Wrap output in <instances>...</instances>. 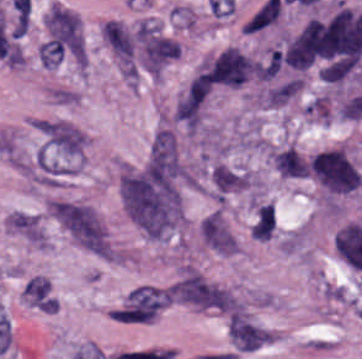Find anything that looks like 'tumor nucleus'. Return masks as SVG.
<instances>
[{
    "instance_id": "obj_3",
    "label": "tumor nucleus",
    "mask_w": 362,
    "mask_h": 359,
    "mask_svg": "<svg viewBox=\"0 0 362 359\" xmlns=\"http://www.w3.org/2000/svg\"><path fill=\"white\" fill-rule=\"evenodd\" d=\"M269 159L274 169L289 178L306 177L304 156L294 146H285L269 152Z\"/></svg>"
},
{
    "instance_id": "obj_2",
    "label": "tumor nucleus",
    "mask_w": 362,
    "mask_h": 359,
    "mask_svg": "<svg viewBox=\"0 0 362 359\" xmlns=\"http://www.w3.org/2000/svg\"><path fill=\"white\" fill-rule=\"evenodd\" d=\"M254 69L252 58L234 47H227L204 71L211 82L239 86Z\"/></svg>"
},
{
    "instance_id": "obj_1",
    "label": "tumor nucleus",
    "mask_w": 362,
    "mask_h": 359,
    "mask_svg": "<svg viewBox=\"0 0 362 359\" xmlns=\"http://www.w3.org/2000/svg\"><path fill=\"white\" fill-rule=\"evenodd\" d=\"M309 174L332 195L349 194L362 186V173L346 148L332 146L305 160Z\"/></svg>"
}]
</instances>
